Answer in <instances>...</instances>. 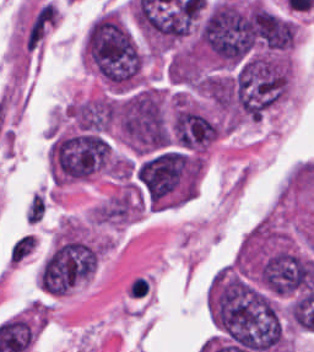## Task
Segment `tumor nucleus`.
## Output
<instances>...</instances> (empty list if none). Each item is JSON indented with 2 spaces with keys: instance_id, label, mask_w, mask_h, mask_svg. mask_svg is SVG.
Segmentation results:
<instances>
[{
  "instance_id": "2f306a5c",
  "label": "tumor nucleus",
  "mask_w": 314,
  "mask_h": 352,
  "mask_svg": "<svg viewBox=\"0 0 314 352\" xmlns=\"http://www.w3.org/2000/svg\"><path fill=\"white\" fill-rule=\"evenodd\" d=\"M81 56L107 85L129 87L140 77L138 45L120 18L110 12H103L87 27Z\"/></svg>"
},
{
  "instance_id": "8643909e",
  "label": "tumor nucleus",
  "mask_w": 314,
  "mask_h": 352,
  "mask_svg": "<svg viewBox=\"0 0 314 352\" xmlns=\"http://www.w3.org/2000/svg\"><path fill=\"white\" fill-rule=\"evenodd\" d=\"M109 119L129 150L147 153L168 145L164 106L152 85L132 87L109 98Z\"/></svg>"
}]
</instances>
